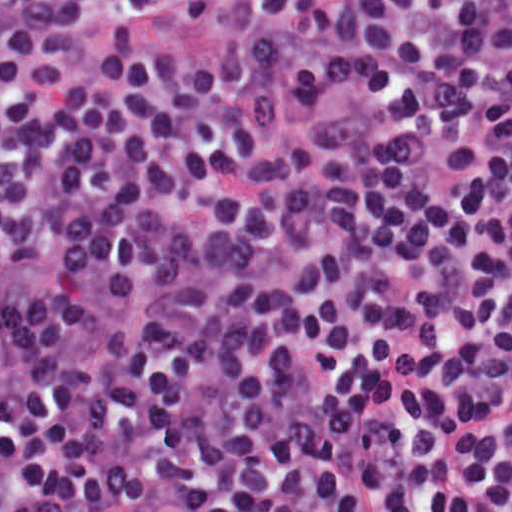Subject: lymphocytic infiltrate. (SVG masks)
<instances>
[{"label":"lymphocytic infiltrate","instance_id":"lymphocytic-infiltrate-1","mask_svg":"<svg viewBox=\"0 0 512 512\" xmlns=\"http://www.w3.org/2000/svg\"><path fill=\"white\" fill-rule=\"evenodd\" d=\"M0 512H512V0H0Z\"/></svg>","mask_w":512,"mask_h":512}]
</instances>
